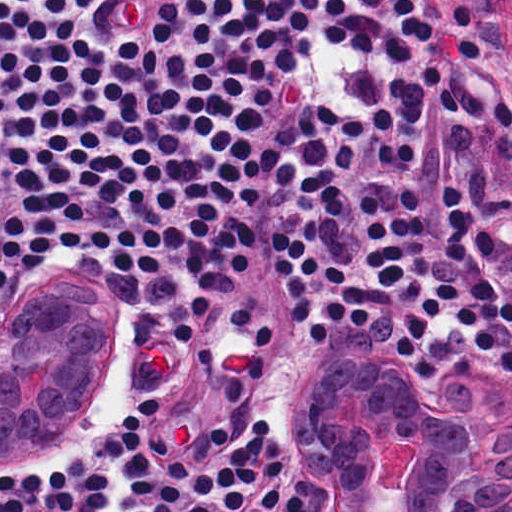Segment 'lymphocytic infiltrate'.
<instances>
[{
  "label": "lymphocytic infiltrate",
  "instance_id": "lymphocytic-infiltrate-1",
  "mask_svg": "<svg viewBox=\"0 0 512 512\" xmlns=\"http://www.w3.org/2000/svg\"><path fill=\"white\" fill-rule=\"evenodd\" d=\"M316 0H0V297L23 266L98 253L127 275L200 266L237 174L277 153L262 112L316 45ZM437 0H324V38L408 63ZM272 185L294 196L272 274L312 344L338 323L408 370L487 354L512 379L509 100L482 103L442 63L345 110L290 121ZM161 405L137 402L104 446L60 469L0 476V512H280V445L264 417L236 442L215 422L183 454Z\"/></svg>",
  "mask_w": 512,
  "mask_h": 512
}]
</instances>
